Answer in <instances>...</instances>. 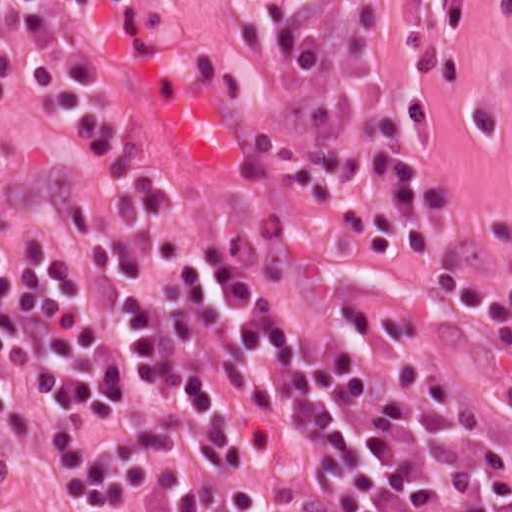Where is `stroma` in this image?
Masks as SVG:
<instances>
[{"instance_id": "1", "label": "stroma", "mask_w": 512, "mask_h": 512, "mask_svg": "<svg viewBox=\"0 0 512 512\" xmlns=\"http://www.w3.org/2000/svg\"><path fill=\"white\" fill-rule=\"evenodd\" d=\"M258 0H169L110 10L47 0L40 19L4 3L0 131L43 158L71 147L48 106L57 77L105 83L134 136L142 173L197 240L268 262L440 359L467 414L512 432V352L495 323L432 290L402 250L360 248L346 215L359 191L313 212L263 113ZM431 111L430 138L404 149L453 193L441 230L454 265L512 277V0H418L405 87ZM0 512H33L31 472L0 438Z\"/></svg>"}]
</instances>
